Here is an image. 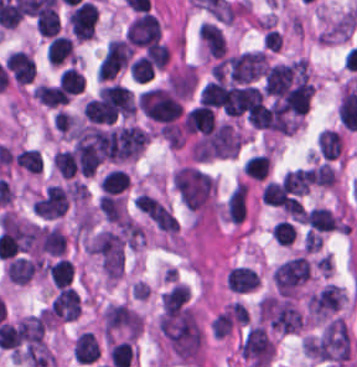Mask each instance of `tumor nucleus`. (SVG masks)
Returning <instances> with one entry per match:
<instances>
[{
	"label": "tumor nucleus",
	"mask_w": 357,
	"mask_h": 367,
	"mask_svg": "<svg viewBox=\"0 0 357 367\" xmlns=\"http://www.w3.org/2000/svg\"><path fill=\"white\" fill-rule=\"evenodd\" d=\"M159 328L176 358L180 361L199 362L201 330L192 310L181 306L160 315Z\"/></svg>",
	"instance_id": "1"
},
{
	"label": "tumor nucleus",
	"mask_w": 357,
	"mask_h": 367,
	"mask_svg": "<svg viewBox=\"0 0 357 367\" xmlns=\"http://www.w3.org/2000/svg\"><path fill=\"white\" fill-rule=\"evenodd\" d=\"M104 134L95 125H82L77 131L64 161L73 172L93 175L99 162Z\"/></svg>",
	"instance_id": "2"
},
{
	"label": "tumor nucleus",
	"mask_w": 357,
	"mask_h": 367,
	"mask_svg": "<svg viewBox=\"0 0 357 367\" xmlns=\"http://www.w3.org/2000/svg\"><path fill=\"white\" fill-rule=\"evenodd\" d=\"M240 138L232 124L216 123L191 146L193 160H209L229 157L240 146Z\"/></svg>",
	"instance_id": "3"
},
{
	"label": "tumor nucleus",
	"mask_w": 357,
	"mask_h": 367,
	"mask_svg": "<svg viewBox=\"0 0 357 367\" xmlns=\"http://www.w3.org/2000/svg\"><path fill=\"white\" fill-rule=\"evenodd\" d=\"M147 134L140 128L124 125L104 129L99 157L120 161L140 152L146 142Z\"/></svg>",
	"instance_id": "4"
},
{
	"label": "tumor nucleus",
	"mask_w": 357,
	"mask_h": 367,
	"mask_svg": "<svg viewBox=\"0 0 357 367\" xmlns=\"http://www.w3.org/2000/svg\"><path fill=\"white\" fill-rule=\"evenodd\" d=\"M172 179L179 198L190 208L197 209L214 186L211 177L193 166H180Z\"/></svg>",
	"instance_id": "5"
},
{
	"label": "tumor nucleus",
	"mask_w": 357,
	"mask_h": 367,
	"mask_svg": "<svg viewBox=\"0 0 357 367\" xmlns=\"http://www.w3.org/2000/svg\"><path fill=\"white\" fill-rule=\"evenodd\" d=\"M105 276L115 279L122 272V239L116 232L102 229L88 246Z\"/></svg>",
	"instance_id": "6"
},
{
	"label": "tumor nucleus",
	"mask_w": 357,
	"mask_h": 367,
	"mask_svg": "<svg viewBox=\"0 0 357 367\" xmlns=\"http://www.w3.org/2000/svg\"><path fill=\"white\" fill-rule=\"evenodd\" d=\"M258 317L279 330H298L302 319L300 311L286 298L263 295L259 301Z\"/></svg>",
	"instance_id": "7"
},
{
	"label": "tumor nucleus",
	"mask_w": 357,
	"mask_h": 367,
	"mask_svg": "<svg viewBox=\"0 0 357 367\" xmlns=\"http://www.w3.org/2000/svg\"><path fill=\"white\" fill-rule=\"evenodd\" d=\"M46 320L44 313L28 315L19 320L10 331L16 357H21L44 345Z\"/></svg>",
	"instance_id": "8"
},
{
	"label": "tumor nucleus",
	"mask_w": 357,
	"mask_h": 367,
	"mask_svg": "<svg viewBox=\"0 0 357 367\" xmlns=\"http://www.w3.org/2000/svg\"><path fill=\"white\" fill-rule=\"evenodd\" d=\"M316 357L345 360L349 355L348 331L342 317L326 324L314 344Z\"/></svg>",
	"instance_id": "9"
},
{
	"label": "tumor nucleus",
	"mask_w": 357,
	"mask_h": 367,
	"mask_svg": "<svg viewBox=\"0 0 357 367\" xmlns=\"http://www.w3.org/2000/svg\"><path fill=\"white\" fill-rule=\"evenodd\" d=\"M142 327L139 313L124 304H109L103 310V329L109 338H135Z\"/></svg>",
	"instance_id": "10"
},
{
	"label": "tumor nucleus",
	"mask_w": 357,
	"mask_h": 367,
	"mask_svg": "<svg viewBox=\"0 0 357 367\" xmlns=\"http://www.w3.org/2000/svg\"><path fill=\"white\" fill-rule=\"evenodd\" d=\"M271 278L279 295H290L307 278V261L300 255H293L272 269Z\"/></svg>",
	"instance_id": "11"
},
{
	"label": "tumor nucleus",
	"mask_w": 357,
	"mask_h": 367,
	"mask_svg": "<svg viewBox=\"0 0 357 367\" xmlns=\"http://www.w3.org/2000/svg\"><path fill=\"white\" fill-rule=\"evenodd\" d=\"M226 66L232 82L249 83L264 73L267 63L263 50H255L226 57Z\"/></svg>",
	"instance_id": "12"
},
{
	"label": "tumor nucleus",
	"mask_w": 357,
	"mask_h": 367,
	"mask_svg": "<svg viewBox=\"0 0 357 367\" xmlns=\"http://www.w3.org/2000/svg\"><path fill=\"white\" fill-rule=\"evenodd\" d=\"M243 357L257 364L267 366L274 354V344L263 326L250 325L239 347Z\"/></svg>",
	"instance_id": "13"
},
{
	"label": "tumor nucleus",
	"mask_w": 357,
	"mask_h": 367,
	"mask_svg": "<svg viewBox=\"0 0 357 367\" xmlns=\"http://www.w3.org/2000/svg\"><path fill=\"white\" fill-rule=\"evenodd\" d=\"M130 58L129 45L122 38H109L97 64L98 80H106L122 69Z\"/></svg>",
	"instance_id": "14"
},
{
	"label": "tumor nucleus",
	"mask_w": 357,
	"mask_h": 367,
	"mask_svg": "<svg viewBox=\"0 0 357 367\" xmlns=\"http://www.w3.org/2000/svg\"><path fill=\"white\" fill-rule=\"evenodd\" d=\"M160 37V24L151 15L141 12L126 25L124 39L134 46H145Z\"/></svg>",
	"instance_id": "15"
},
{
	"label": "tumor nucleus",
	"mask_w": 357,
	"mask_h": 367,
	"mask_svg": "<svg viewBox=\"0 0 357 367\" xmlns=\"http://www.w3.org/2000/svg\"><path fill=\"white\" fill-rule=\"evenodd\" d=\"M134 206L157 228L173 233L177 230V223L171 212L148 194L140 192L134 198Z\"/></svg>",
	"instance_id": "16"
},
{
	"label": "tumor nucleus",
	"mask_w": 357,
	"mask_h": 367,
	"mask_svg": "<svg viewBox=\"0 0 357 367\" xmlns=\"http://www.w3.org/2000/svg\"><path fill=\"white\" fill-rule=\"evenodd\" d=\"M67 204V189L57 184H49L32 205V210L36 214L53 218L62 216Z\"/></svg>",
	"instance_id": "17"
},
{
	"label": "tumor nucleus",
	"mask_w": 357,
	"mask_h": 367,
	"mask_svg": "<svg viewBox=\"0 0 357 367\" xmlns=\"http://www.w3.org/2000/svg\"><path fill=\"white\" fill-rule=\"evenodd\" d=\"M343 295L338 284L328 282L310 292L306 300V309L315 316L323 317L339 304Z\"/></svg>",
	"instance_id": "18"
},
{
	"label": "tumor nucleus",
	"mask_w": 357,
	"mask_h": 367,
	"mask_svg": "<svg viewBox=\"0 0 357 367\" xmlns=\"http://www.w3.org/2000/svg\"><path fill=\"white\" fill-rule=\"evenodd\" d=\"M80 298L73 286H59L49 303V315L74 320L78 316Z\"/></svg>",
	"instance_id": "19"
},
{
	"label": "tumor nucleus",
	"mask_w": 357,
	"mask_h": 367,
	"mask_svg": "<svg viewBox=\"0 0 357 367\" xmlns=\"http://www.w3.org/2000/svg\"><path fill=\"white\" fill-rule=\"evenodd\" d=\"M5 68L21 84L34 77V60L24 50H11L6 56Z\"/></svg>",
	"instance_id": "20"
},
{
	"label": "tumor nucleus",
	"mask_w": 357,
	"mask_h": 367,
	"mask_svg": "<svg viewBox=\"0 0 357 367\" xmlns=\"http://www.w3.org/2000/svg\"><path fill=\"white\" fill-rule=\"evenodd\" d=\"M304 222L310 233L336 230L339 220L338 216L327 208L312 206L304 211Z\"/></svg>",
	"instance_id": "21"
},
{
	"label": "tumor nucleus",
	"mask_w": 357,
	"mask_h": 367,
	"mask_svg": "<svg viewBox=\"0 0 357 367\" xmlns=\"http://www.w3.org/2000/svg\"><path fill=\"white\" fill-rule=\"evenodd\" d=\"M197 35L208 56L222 58L225 38L218 25L208 21H201L198 24Z\"/></svg>",
	"instance_id": "22"
},
{
	"label": "tumor nucleus",
	"mask_w": 357,
	"mask_h": 367,
	"mask_svg": "<svg viewBox=\"0 0 357 367\" xmlns=\"http://www.w3.org/2000/svg\"><path fill=\"white\" fill-rule=\"evenodd\" d=\"M65 236L56 225L41 226L38 228V250L48 255L64 253Z\"/></svg>",
	"instance_id": "23"
},
{
	"label": "tumor nucleus",
	"mask_w": 357,
	"mask_h": 367,
	"mask_svg": "<svg viewBox=\"0 0 357 367\" xmlns=\"http://www.w3.org/2000/svg\"><path fill=\"white\" fill-rule=\"evenodd\" d=\"M258 281V273L248 265H234L226 277L227 287L233 291H248Z\"/></svg>",
	"instance_id": "24"
},
{
	"label": "tumor nucleus",
	"mask_w": 357,
	"mask_h": 367,
	"mask_svg": "<svg viewBox=\"0 0 357 367\" xmlns=\"http://www.w3.org/2000/svg\"><path fill=\"white\" fill-rule=\"evenodd\" d=\"M31 94L43 105L53 108L67 103L69 99L62 88L53 84L37 83Z\"/></svg>",
	"instance_id": "25"
},
{
	"label": "tumor nucleus",
	"mask_w": 357,
	"mask_h": 367,
	"mask_svg": "<svg viewBox=\"0 0 357 367\" xmlns=\"http://www.w3.org/2000/svg\"><path fill=\"white\" fill-rule=\"evenodd\" d=\"M316 145L324 159H333L341 149L338 131L322 128L316 134Z\"/></svg>",
	"instance_id": "26"
},
{
	"label": "tumor nucleus",
	"mask_w": 357,
	"mask_h": 367,
	"mask_svg": "<svg viewBox=\"0 0 357 367\" xmlns=\"http://www.w3.org/2000/svg\"><path fill=\"white\" fill-rule=\"evenodd\" d=\"M306 173L311 183L321 187H332L336 180L333 167L322 161L307 167Z\"/></svg>",
	"instance_id": "27"
},
{
	"label": "tumor nucleus",
	"mask_w": 357,
	"mask_h": 367,
	"mask_svg": "<svg viewBox=\"0 0 357 367\" xmlns=\"http://www.w3.org/2000/svg\"><path fill=\"white\" fill-rule=\"evenodd\" d=\"M59 15L54 7H47L38 14L35 28L41 36H52L58 33Z\"/></svg>",
	"instance_id": "28"
},
{
	"label": "tumor nucleus",
	"mask_w": 357,
	"mask_h": 367,
	"mask_svg": "<svg viewBox=\"0 0 357 367\" xmlns=\"http://www.w3.org/2000/svg\"><path fill=\"white\" fill-rule=\"evenodd\" d=\"M309 184L310 182L306 176L305 171L297 167L286 170L285 173L281 176V186L294 192H298L301 194L307 192Z\"/></svg>",
	"instance_id": "29"
},
{
	"label": "tumor nucleus",
	"mask_w": 357,
	"mask_h": 367,
	"mask_svg": "<svg viewBox=\"0 0 357 367\" xmlns=\"http://www.w3.org/2000/svg\"><path fill=\"white\" fill-rule=\"evenodd\" d=\"M273 237L279 245H289L294 237V228L289 221L279 220L271 227Z\"/></svg>",
	"instance_id": "30"
}]
</instances>
